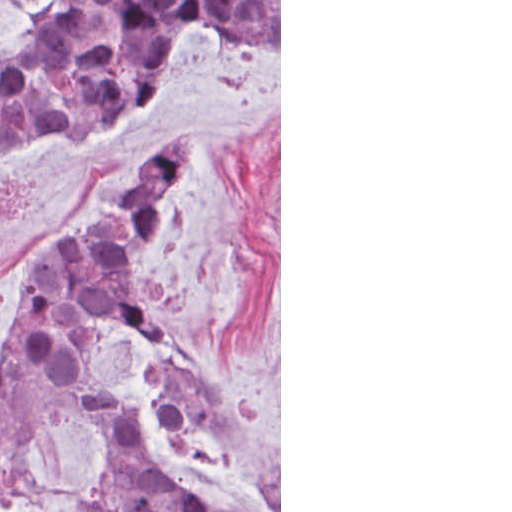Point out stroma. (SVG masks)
<instances>
[{"label":"stroma","mask_w":512,"mask_h":512,"mask_svg":"<svg viewBox=\"0 0 512 512\" xmlns=\"http://www.w3.org/2000/svg\"><path fill=\"white\" fill-rule=\"evenodd\" d=\"M61 0H0V40ZM193 131L159 234L135 261L149 311L279 453V510L238 459L172 439L154 408L160 364L119 333L96 363L136 386L139 427L173 483L213 512H281V0L279 53L263 63L185 35L139 110L70 141L0 161V349L17 324L23 268L60 231L135 188L159 148ZM19 462L0 512H95L107 417L68 391L19 396Z\"/></svg>","instance_id":"35a3bbf8"}]
</instances>
